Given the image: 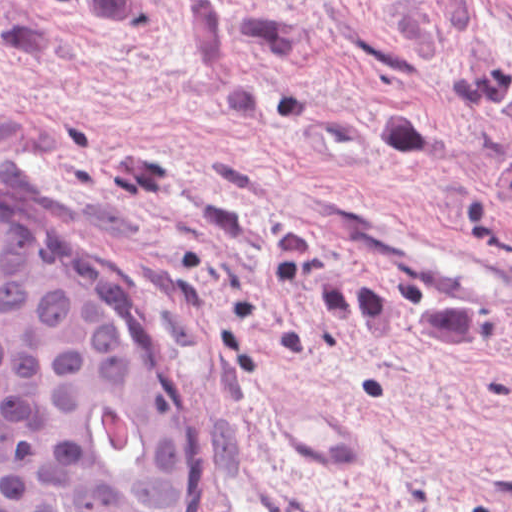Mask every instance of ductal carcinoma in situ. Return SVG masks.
<instances>
[{
  "mask_svg": "<svg viewBox=\"0 0 512 512\" xmlns=\"http://www.w3.org/2000/svg\"><path fill=\"white\" fill-rule=\"evenodd\" d=\"M201 410L80 242L0 205V512H182Z\"/></svg>",
  "mask_w": 512,
  "mask_h": 512,
  "instance_id": "0f090b9a",
  "label": "ductal carcinoma in situ"
}]
</instances>
